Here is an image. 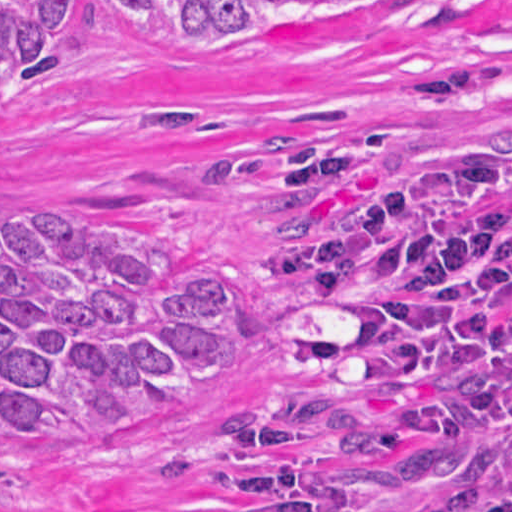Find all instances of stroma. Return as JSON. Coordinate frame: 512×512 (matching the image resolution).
Wrapping results in <instances>:
<instances>
[{
	"label": "stroma",
	"mask_w": 512,
	"mask_h": 512,
	"mask_svg": "<svg viewBox=\"0 0 512 512\" xmlns=\"http://www.w3.org/2000/svg\"><path fill=\"white\" fill-rule=\"evenodd\" d=\"M466 144L512 165V0H420L234 63L122 48L82 0L51 68L0 94V207L226 261L254 327L226 370L128 427L0 441V512H471L512 454V357L408 352L353 306L292 304L269 196V179L284 198L363 195Z\"/></svg>",
	"instance_id": "1"
}]
</instances>
